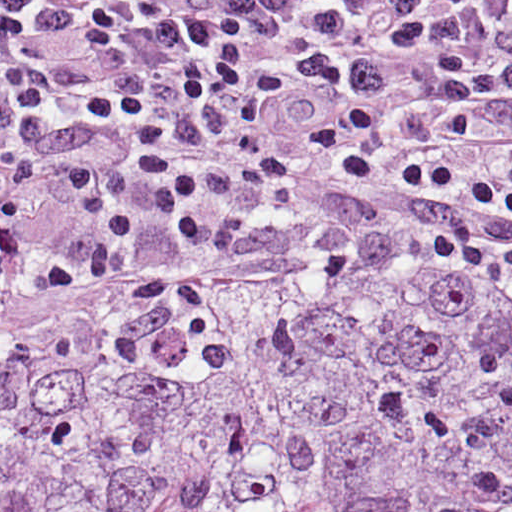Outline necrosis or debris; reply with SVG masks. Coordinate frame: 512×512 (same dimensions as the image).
<instances>
[{"mask_svg":"<svg viewBox=\"0 0 512 512\" xmlns=\"http://www.w3.org/2000/svg\"><path fill=\"white\" fill-rule=\"evenodd\" d=\"M351 242H354V241H349L347 244H349ZM339 248H341V247H339ZM339 248H337V249H339ZM337 249L332 250V251L324 254L323 256H321L318 259L305 260V261H300V262H268V263H264V264H260V265H256V266H252V267H248V268H242L241 270H244V271H262V272H303L309 266H311L314 262H316L319 259H321L322 257H324V256H326V255L336 251ZM70 293H72V292H70ZM70 293H66V294H62V295H59V296H55V297L51 298L50 300H48L47 302H45V303H43L41 305H44V304L49 303L51 301H54V300H56L58 298H61L62 296L70 294ZM41 305H38L36 307H39ZM36 307L1 313L0 314V323H3L5 321H7V320H11L12 318H14V317H16V316L26 312V311L34 309Z\"/></svg>","mask_w":512,"mask_h":512,"instance_id":"1","label":"necrosis or debris"}]
</instances>
